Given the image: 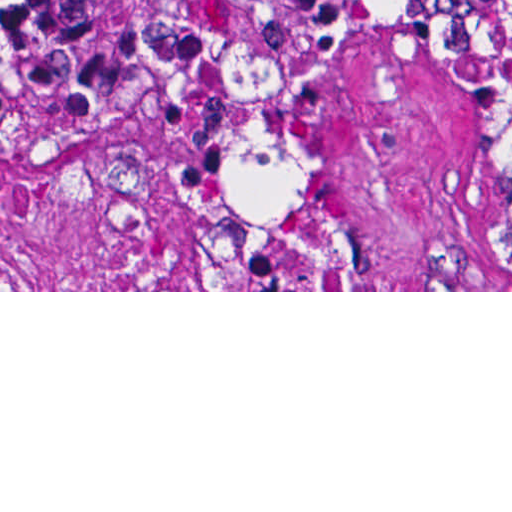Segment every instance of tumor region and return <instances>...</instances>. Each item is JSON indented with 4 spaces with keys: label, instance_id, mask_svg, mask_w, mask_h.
<instances>
[{
    "label": "tumor region",
    "instance_id": "e687c5a6",
    "mask_svg": "<svg viewBox=\"0 0 512 512\" xmlns=\"http://www.w3.org/2000/svg\"><path fill=\"white\" fill-rule=\"evenodd\" d=\"M445 0H0V75L57 113H148L217 57L324 44Z\"/></svg>",
    "mask_w": 512,
    "mask_h": 512
}]
</instances>
